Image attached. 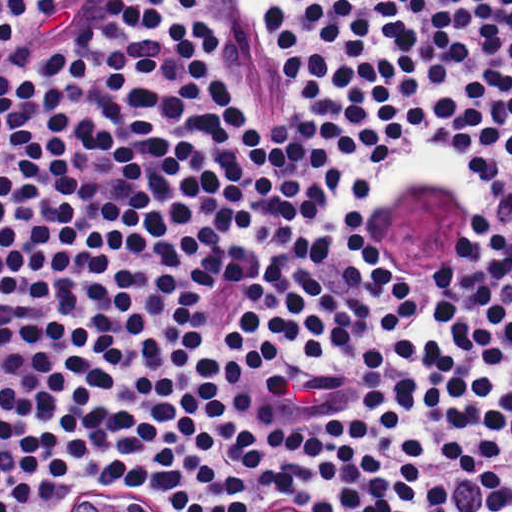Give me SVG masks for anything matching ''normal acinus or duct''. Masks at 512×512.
<instances>
[{
	"label": "normal acinus or duct",
	"instance_id": "1",
	"mask_svg": "<svg viewBox=\"0 0 512 512\" xmlns=\"http://www.w3.org/2000/svg\"><path fill=\"white\" fill-rule=\"evenodd\" d=\"M68 499L62 512H142L130 495L104 487H84Z\"/></svg>",
	"mask_w": 512,
	"mask_h": 512
}]
</instances>
